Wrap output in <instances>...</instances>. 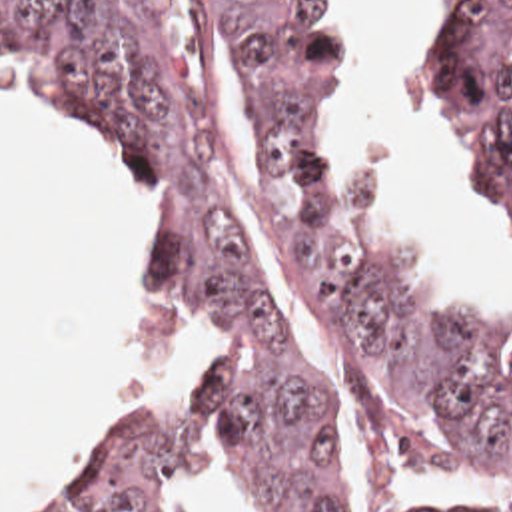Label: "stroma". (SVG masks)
<instances>
[{
	"mask_svg": "<svg viewBox=\"0 0 512 512\" xmlns=\"http://www.w3.org/2000/svg\"><path fill=\"white\" fill-rule=\"evenodd\" d=\"M447 1L449 0L411 1L403 17L395 51H393V81H395V93H397L403 125L429 177L443 189L449 213L459 223L477 261L481 263L497 295L499 317H475L455 301V297L447 291L441 279L417 255L389 199L381 189V165L377 157V123L369 111V99H367V51L363 43L357 0H345L347 183H349V193L353 197L355 209L365 229L369 231L373 243L387 257V261L397 269V273L407 281V285L413 291L427 297L429 301L437 303L455 321H459L485 349H489L501 361L512 365V341L507 329V295H509V281L512 275L511 251L481 197L473 169L463 161V157L453 147L429 135L405 103V43L413 33V29L417 27L419 19ZM186 63L194 67L192 57L186 59ZM0 77L14 85L28 87L14 71L0 69Z\"/></svg>",
	"mask_w": 512,
	"mask_h": 512,
	"instance_id": "obj_1",
	"label": "stroma"
}]
</instances>
